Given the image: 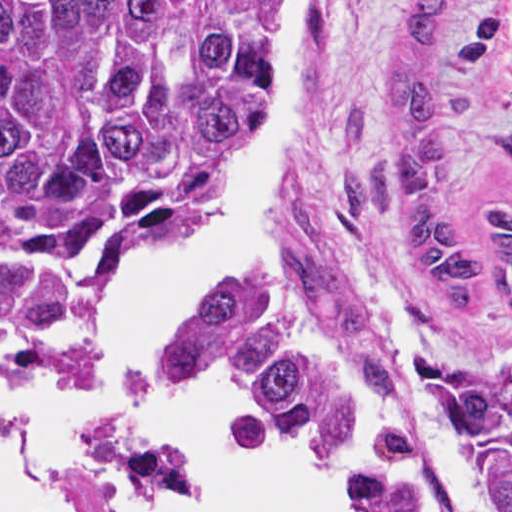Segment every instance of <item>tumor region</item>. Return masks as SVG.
Segmentation results:
<instances>
[{"instance_id": "tumor-region-1", "label": "tumor region", "mask_w": 512, "mask_h": 512, "mask_svg": "<svg viewBox=\"0 0 512 512\" xmlns=\"http://www.w3.org/2000/svg\"><path fill=\"white\" fill-rule=\"evenodd\" d=\"M304 2L299 12V41ZM457 0H408L383 118L393 154L346 204L401 221L405 256L447 306L478 313L498 261L512 319V206L482 232L442 207L439 46ZM276 0H0V348L62 337L100 284L202 212L237 159L274 59ZM234 398L309 454L341 512H450L422 433L269 292L219 297L156 389ZM442 438L472 512H512V337L442 385Z\"/></svg>"}]
</instances>
